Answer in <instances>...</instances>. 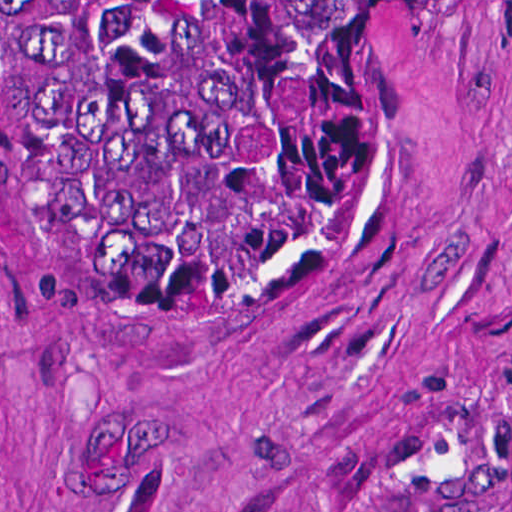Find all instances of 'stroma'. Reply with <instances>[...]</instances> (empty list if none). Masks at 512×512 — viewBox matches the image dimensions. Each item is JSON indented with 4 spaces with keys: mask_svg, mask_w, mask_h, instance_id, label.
Here are the masks:
<instances>
[{
    "mask_svg": "<svg viewBox=\"0 0 512 512\" xmlns=\"http://www.w3.org/2000/svg\"><path fill=\"white\" fill-rule=\"evenodd\" d=\"M0 512H512V0L361 34L338 189L223 351L107 335L0 154Z\"/></svg>",
    "mask_w": 512,
    "mask_h": 512,
    "instance_id": "obj_1",
    "label": "stroma"
}]
</instances>
